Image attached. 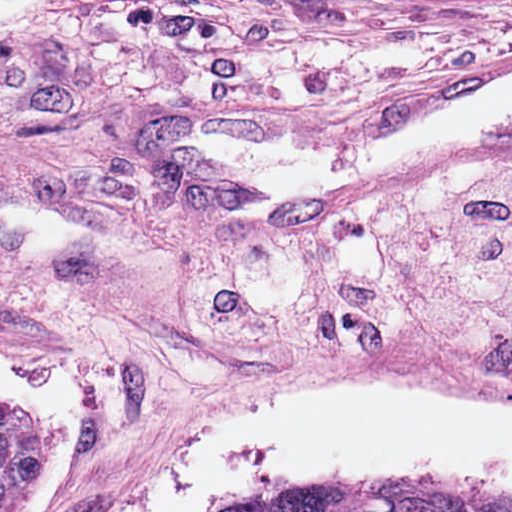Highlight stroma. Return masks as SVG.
<instances>
[{
  "label": "stroma",
  "instance_id": "1",
  "mask_svg": "<svg viewBox=\"0 0 512 512\" xmlns=\"http://www.w3.org/2000/svg\"><path fill=\"white\" fill-rule=\"evenodd\" d=\"M512 71V5L19 22L0 29V361L65 365L89 426L59 512H132L248 411L320 378L429 376L512 408V360L415 335L365 356L223 347L142 295L512 145L412 153L301 195L243 187L178 133L313 150Z\"/></svg>",
  "mask_w": 512,
  "mask_h": 512
}]
</instances>
